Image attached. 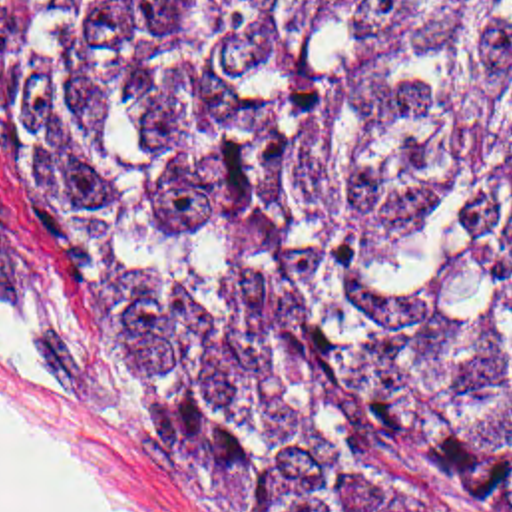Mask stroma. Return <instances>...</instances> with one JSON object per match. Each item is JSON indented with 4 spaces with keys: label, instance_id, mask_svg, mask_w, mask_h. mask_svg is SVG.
<instances>
[{
    "label": "stroma",
    "instance_id": "stroma-1",
    "mask_svg": "<svg viewBox=\"0 0 512 512\" xmlns=\"http://www.w3.org/2000/svg\"><path fill=\"white\" fill-rule=\"evenodd\" d=\"M1 0V9L5 5ZM0 298L67 384L0 344V412L65 477L118 512H228L156 380L110 332L73 270L11 205L0 177Z\"/></svg>",
    "mask_w": 512,
    "mask_h": 512
}]
</instances>
